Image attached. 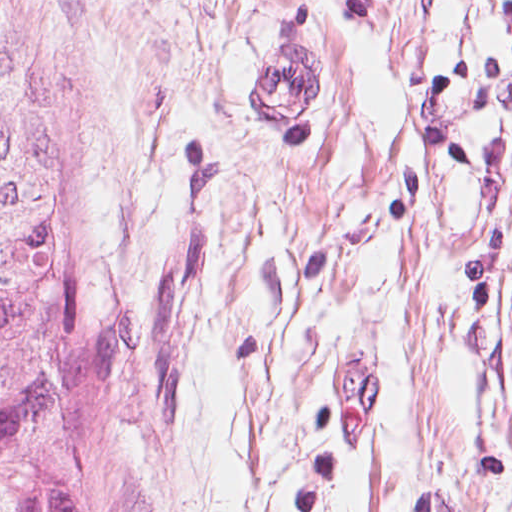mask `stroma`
<instances>
[{"mask_svg":"<svg viewBox=\"0 0 512 512\" xmlns=\"http://www.w3.org/2000/svg\"><path fill=\"white\" fill-rule=\"evenodd\" d=\"M31 2L139 512H512V0ZM280 54L303 125L251 93Z\"/></svg>","mask_w":512,"mask_h":512,"instance_id":"obj_1","label":"stroma"}]
</instances>
